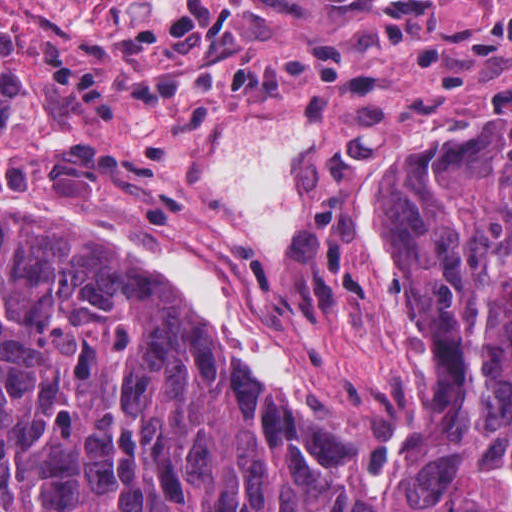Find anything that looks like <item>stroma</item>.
Returning <instances> with one entry per match:
<instances>
[{
    "instance_id": "stroma-1",
    "label": "stroma",
    "mask_w": 512,
    "mask_h": 512,
    "mask_svg": "<svg viewBox=\"0 0 512 512\" xmlns=\"http://www.w3.org/2000/svg\"><path fill=\"white\" fill-rule=\"evenodd\" d=\"M10 1L24 87L0 111V209L216 163L218 135L246 118L307 115L323 140L449 113L475 97H512V0H215L246 12V63L338 52V87H109L94 113L40 76L35 41L58 35L80 63H104L137 29L191 0L0 3Z\"/></svg>"
}]
</instances>
